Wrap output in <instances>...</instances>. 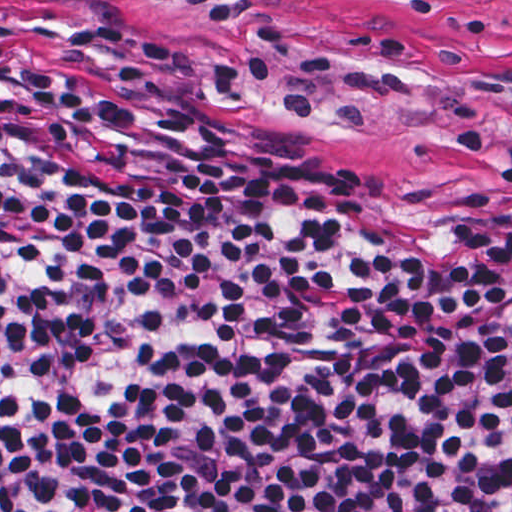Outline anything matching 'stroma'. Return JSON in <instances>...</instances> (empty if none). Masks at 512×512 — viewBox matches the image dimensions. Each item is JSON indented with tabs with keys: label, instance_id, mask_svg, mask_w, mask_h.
<instances>
[{
	"label": "stroma",
	"instance_id": "1",
	"mask_svg": "<svg viewBox=\"0 0 512 512\" xmlns=\"http://www.w3.org/2000/svg\"><path fill=\"white\" fill-rule=\"evenodd\" d=\"M0 22L121 54L205 132L404 212L465 223L512 197L454 116L476 101L512 144V0H0Z\"/></svg>",
	"mask_w": 512,
	"mask_h": 512
}]
</instances>
